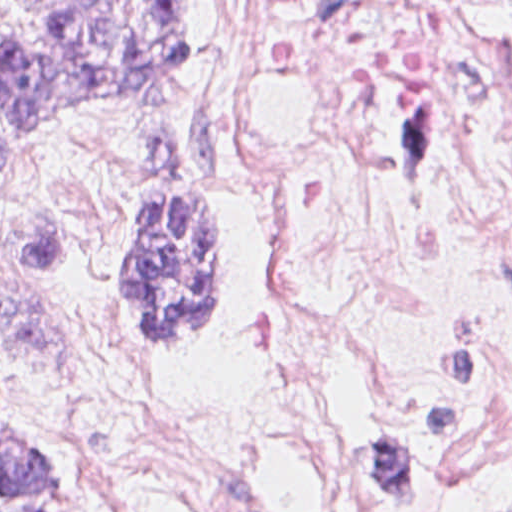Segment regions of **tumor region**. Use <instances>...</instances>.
Instances as JSON below:
<instances>
[{"label":"tumor region","instance_id":"1","mask_svg":"<svg viewBox=\"0 0 512 512\" xmlns=\"http://www.w3.org/2000/svg\"><path fill=\"white\" fill-rule=\"evenodd\" d=\"M195 34L196 0H0V182L32 173L52 126L33 152L41 128L186 83ZM233 240L231 203L217 195L138 198L118 236L116 279L148 346L214 337ZM0 512H90L60 453L1 403Z\"/></svg>","mask_w":512,"mask_h":512}]
</instances>
